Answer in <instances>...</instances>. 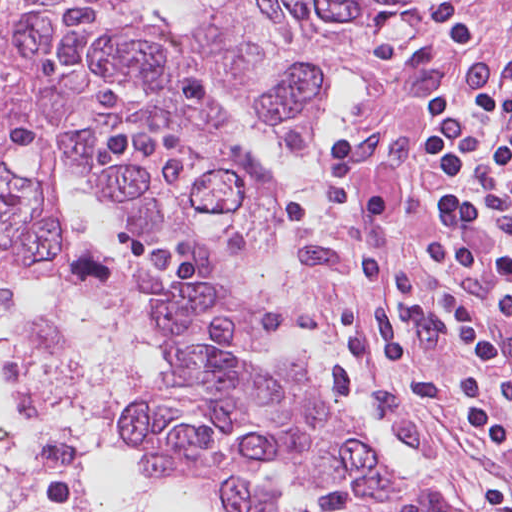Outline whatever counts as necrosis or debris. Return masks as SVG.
Returning a JSON list of instances; mask_svg holds the SVG:
<instances>
[{
	"label": "necrosis or debris",
	"mask_w": 512,
	"mask_h": 512,
	"mask_svg": "<svg viewBox=\"0 0 512 512\" xmlns=\"http://www.w3.org/2000/svg\"><path fill=\"white\" fill-rule=\"evenodd\" d=\"M160 361L118 258L75 252L24 334L0 336V512H104L124 411Z\"/></svg>",
	"instance_id": "1"
}]
</instances>
